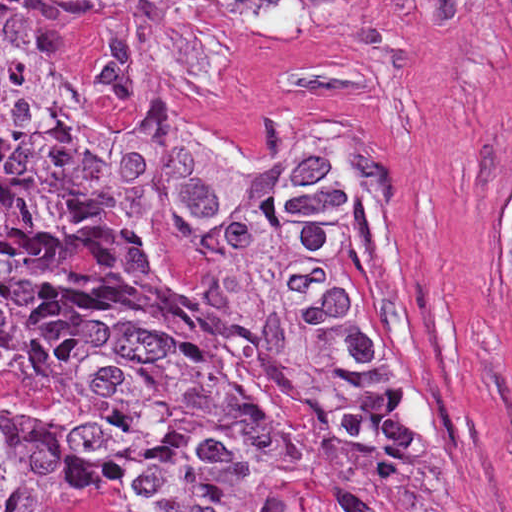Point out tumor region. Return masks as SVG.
<instances>
[{"label":"tumor region","instance_id":"e687c5a6","mask_svg":"<svg viewBox=\"0 0 512 512\" xmlns=\"http://www.w3.org/2000/svg\"><path fill=\"white\" fill-rule=\"evenodd\" d=\"M52 6L103 25L91 95ZM306 1H0V512H478L428 360L377 128L275 153L148 125ZM512 293V204L502 224Z\"/></svg>","mask_w":512,"mask_h":512}]
</instances>
